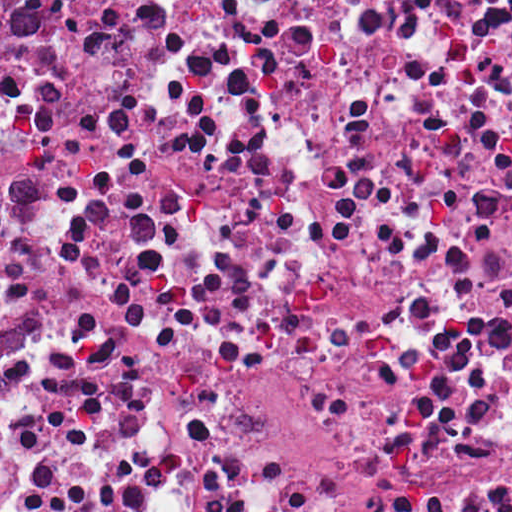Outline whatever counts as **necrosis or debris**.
Returning <instances> with one entry per match:
<instances>
[{
    "instance_id": "necrosis-or-debris-1",
    "label": "necrosis or debris",
    "mask_w": 512,
    "mask_h": 512,
    "mask_svg": "<svg viewBox=\"0 0 512 512\" xmlns=\"http://www.w3.org/2000/svg\"><path fill=\"white\" fill-rule=\"evenodd\" d=\"M0 512H512V0H0Z\"/></svg>"
}]
</instances>
